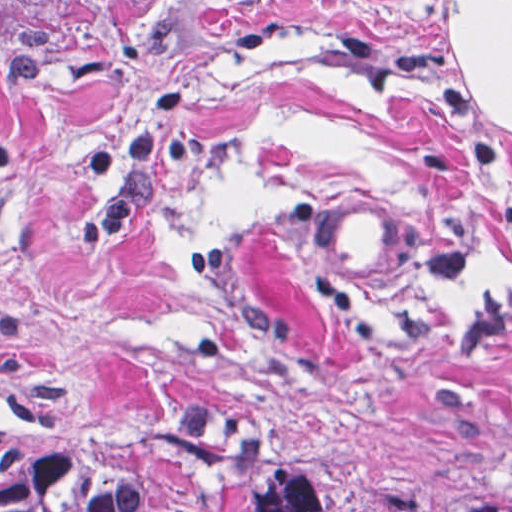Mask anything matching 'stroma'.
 I'll list each match as a JSON object with an SVG mask.
<instances>
[{
    "instance_id": "35a3bbf8",
    "label": "stroma",
    "mask_w": 512,
    "mask_h": 512,
    "mask_svg": "<svg viewBox=\"0 0 512 512\" xmlns=\"http://www.w3.org/2000/svg\"><path fill=\"white\" fill-rule=\"evenodd\" d=\"M315 191L413 230L409 286ZM122 424L512 511V0H78L0 49V440Z\"/></svg>"
}]
</instances>
